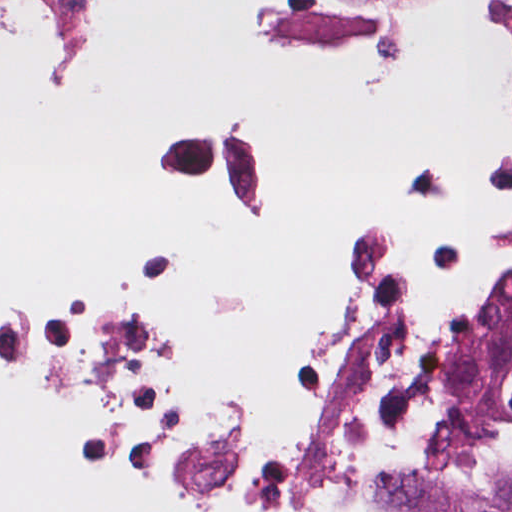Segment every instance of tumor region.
Returning <instances> with one entry per match:
<instances>
[{"mask_svg":"<svg viewBox=\"0 0 512 512\" xmlns=\"http://www.w3.org/2000/svg\"><path fill=\"white\" fill-rule=\"evenodd\" d=\"M490 393L512 421V374ZM390 512H512V483L491 490L463 477L419 479L398 486Z\"/></svg>","mask_w":512,"mask_h":512,"instance_id":"e687c5a6","label":"tumor region"}]
</instances>
